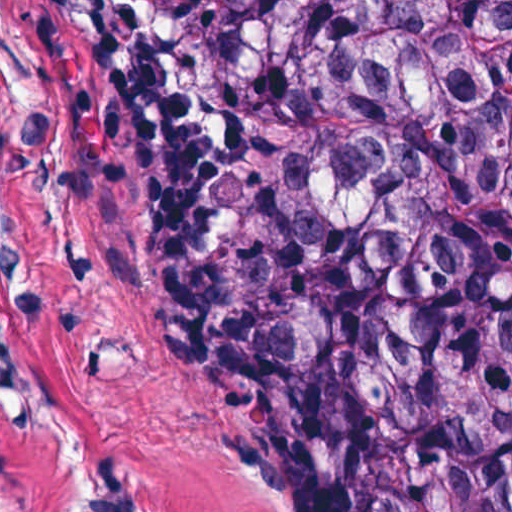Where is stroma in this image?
Instances as JSON below:
<instances>
[{
    "label": "stroma",
    "instance_id": "obj_1",
    "mask_svg": "<svg viewBox=\"0 0 512 512\" xmlns=\"http://www.w3.org/2000/svg\"><path fill=\"white\" fill-rule=\"evenodd\" d=\"M173 1H454L508 44L502 0H0V512H73L78 446L161 512H295L193 357L149 252V179L94 60ZM511 151L512 134L485 281L512 313L497 271Z\"/></svg>",
    "mask_w": 512,
    "mask_h": 512
}]
</instances>
